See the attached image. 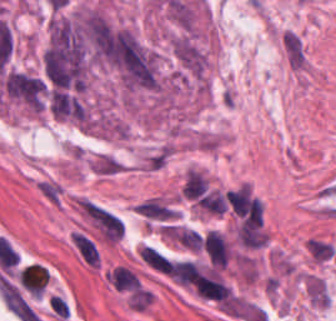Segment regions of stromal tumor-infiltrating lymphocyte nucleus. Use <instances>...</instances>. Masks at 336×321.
Segmentation results:
<instances>
[{"instance_id": "stromal-tumor-infiltrating-lymphocyte-nucleus-1", "label": "stromal tumor-infiltrating lymphocyte nucleus", "mask_w": 336, "mask_h": 321, "mask_svg": "<svg viewBox=\"0 0 336 321\" xmlns=\"http://www.w3.org/2000/svg\"><path fill=\"white\" fill-rule=\"evenodd\" d=\"M21 287L31 296H41L48 280V272L41 264L29 263L16 274Z\"/></svg>"}, {"instance_id": "stromal-tumor-infiltrating-lymphocyte-nucleus-2", "label": "stromal tumor-infiltrating lymphocyte nucleus", "mask_w": 336, "mask_h": 321, "mask_svg": "<svg viewBox=\"0 0 336 321\" xmlns=\"http://www.w3.org/2000/svg\"><path fill=\"white\" fill-rule=\"evenodd\" d=\"M107 276L114 289L138 290L139 283L133 271L123 266H115Z\"/></svg>"}, {"instance_id": "stromal-tumor-infiltrating-lymphocyte-nucleus-3", "label": "stromal tumor-infiltrating lymphocyte nucleus", "mask_w": 336, "mask_h": 321, "mask_svg": "<svg viewBox=\"0 0 336 321\" xmlns=\"http://www.w3.org/2000/svg\"><path fill=\"white\" fill-rule=\"evenodd\" d=\"M140 258L144 263L158 270L163 274H170L171 265L168 259L159 251L150 245H143L140 252Z\"/></svg>"}]
</instances>
